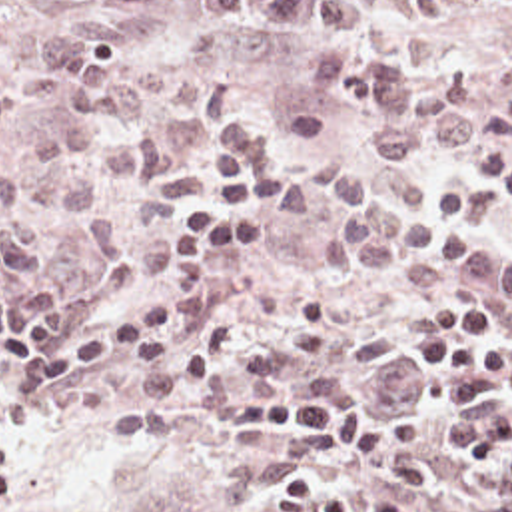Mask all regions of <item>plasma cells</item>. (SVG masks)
Instances as JSON below:
<instances>
[{
  "label": "plasma cells",
  "mask_w": 512,
  "mask_h": 512,
  "mask_svg": "<svg viewBox=\"0 0 512 512\" xmlns=\"http://www.w3.org/2000/svg\"><path fill=\"white\" fill-rule=\"evenodd\" d=\"M13 2L0 0V8ZM91 2L149 16L165 0ZM201 2L225 20L273 16L333 43L321 53L317 73L329 93L352 95L378 115L372 141L378 155L430 161L442 145L456 159H476L474 171L490 189L454 183L434 201L424 197L418 179L358 171L348 155L283 171L269 181L267 195L287 219H307L323 203H335L323 249L341 271L494 301L512 329V243L484 229L488 217L512 219V143L484 153L482 131L468 111L476 89L460 73H416L376 55L362 37L370 14L362 0ZM131 49V24L93 16H75L41 39L39 63L23 77V89L39 105L61 107V117L1 171L0 279L41 267L51 213L85 225L99 259L119 257L117 223L89 209L105 169L133 185H151L169 171L161 135L141 123L169 97V63L147 57L143 91L123 69ZM327 313V295L311 291L267 343L241 355L247 327L235 313L193 359L143 375L135 389L139 403L91 425L93 433L203 423L227 393H325L339 383L327 365L376 363L392 355L384 331H323ZM440 391L448 417L436 421L434 437L460 455L452 479L486 491L480 512H512L510 379L468 369L446 375Z\"/></svg>",
  "instance_id": "obj_1"
}]
</instances>
